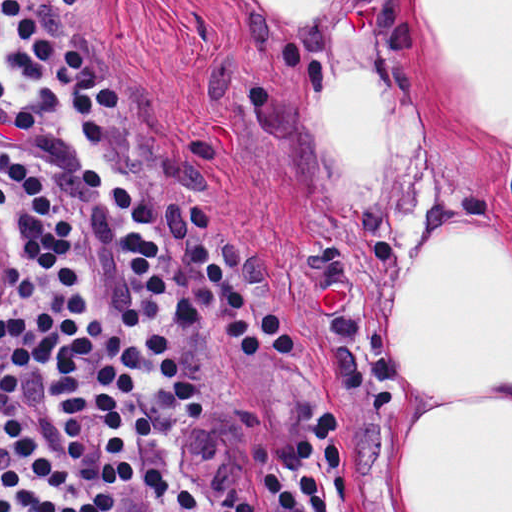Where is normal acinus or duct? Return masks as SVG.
<instances>
[{"label":"normal acinus or duct","instance_id":"normal-acinus-or-duct-1","mask_svg":"<svg viewBox=\"0 0 512 512\" xmlns=\"http://www.w3.org/2000/svg\"><path fill=\"white\" fill-rule=\"evenodd\" d=\"M23 294V238L18 223L0 201V317L12 313Z\"/></svg>","mask_w":512,"mask_h":512}]
</instances>
